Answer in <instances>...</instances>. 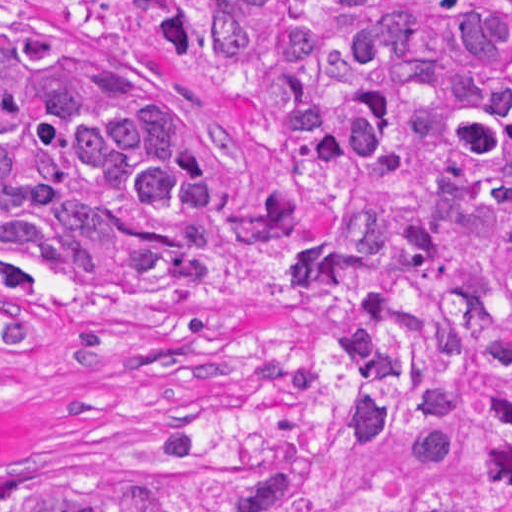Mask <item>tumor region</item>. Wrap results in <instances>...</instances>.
<instances>
[{"instance_id": "e687c5a6", "label": "tumor region", "mask_w": 512, "mask_h": 512, "mask_svg": "<svg viewBox=\"0 0 512 512\" xmlns=\"http://www.w3.org/2000/svg\"><path fill=\"white\" fill-rule=\"evenodd\" d=\"M243 129L293 331L223 313L242 141L175 65L0 0V353L97 453L0 512H512V0H146Z\"/></svg>"}]
</instances>
